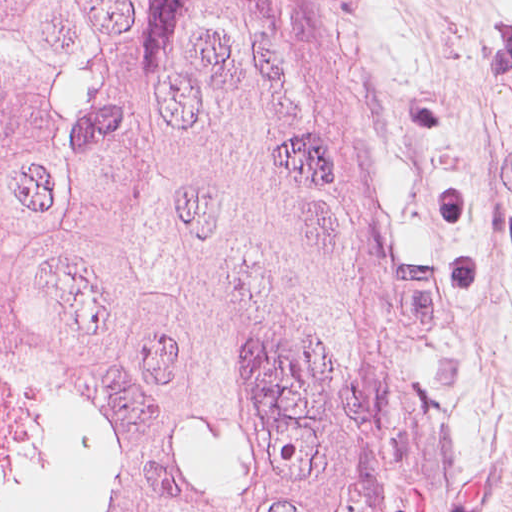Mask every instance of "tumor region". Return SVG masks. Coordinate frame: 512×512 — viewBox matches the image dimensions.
Listing matches in <instances>:
<instances>
[{
    "label": "tumor region",
    "mask_w": 512,
    "mask_h": 512,
    "mask_svg": "<svg viewBox=\"0 0 512 512\" xmlns=\"http://www.w3.org/2000/svg\"><path fill=\"white\" fill-rule=\"evenodd\" d=\"M263 0H0L4 512H376Z\"/></svg>",
    "instance_id": "e687c5a6"
}]
</instances>
